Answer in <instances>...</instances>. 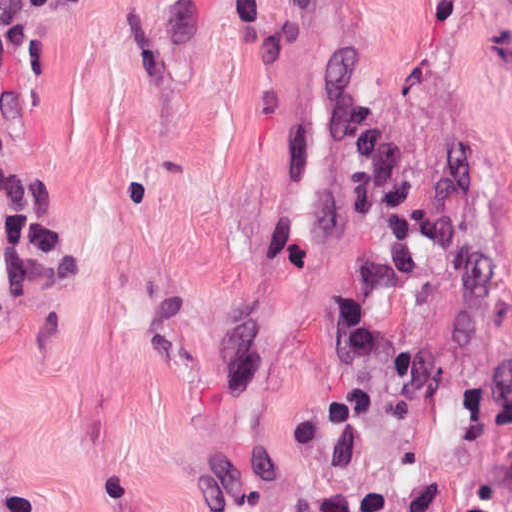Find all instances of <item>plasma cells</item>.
I'll return each mask as SVG.
<instances>
[{"mask_svg":"<svg viewBox=\"0 0 512 512\" xmlns=\"http://www.w3.org/2000/svg\"><path fill=\"white\" fill-rule=\"evenodd\" d=\"M90 0H0V69H37L43 39Z\"/></svg>","mask_w":512,"mask_h":512,"instance_id":"obj_1","label":"plasma cells"}]
</instances>
